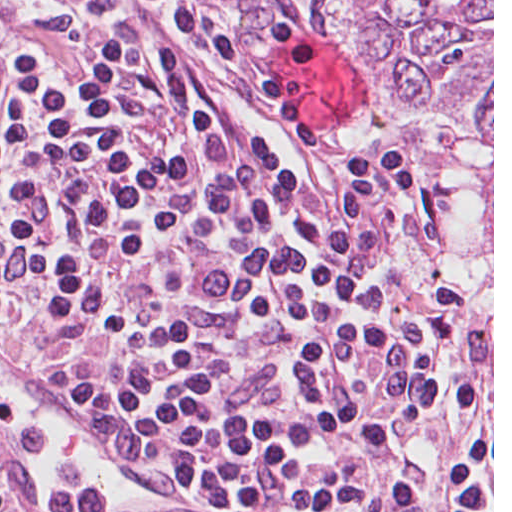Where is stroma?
Instances as JSON below:
<instances>
[{
    "mask_svg": "<svg viewBox=\"0 0 512 512\" xmlns=\"http://www.w3.org/2000/svg\"><path fill=\"white\" fill-rule=\"evenodd\" d=\"M113 1L160 28L217 98L224 113V142L213 163L208 191L235 152L259 138L304 181L330 178L368 153H405L418 172L420 192L388 238L391 261L419 300L437 282L454 280L461 285L368 0H178L213 17L257 62L274 71H279V56L294 42L324 47L349 59L352 117L332 128H318V137L309 146H294L234 71L206 55L154 5L146 0ZM60 366L52 312L40 301L26 300L22 311L0 327V367L40 384ZM485 374L490 373L468 308L439 407ZM66 500L45 499L29 476L0 460V512H58Z\"/></svg>",
    "mask_w": 512,
    "mask_h": 512,
    "instance_id": "obj_1",
    "label": "stroma"
}]
</instances>
